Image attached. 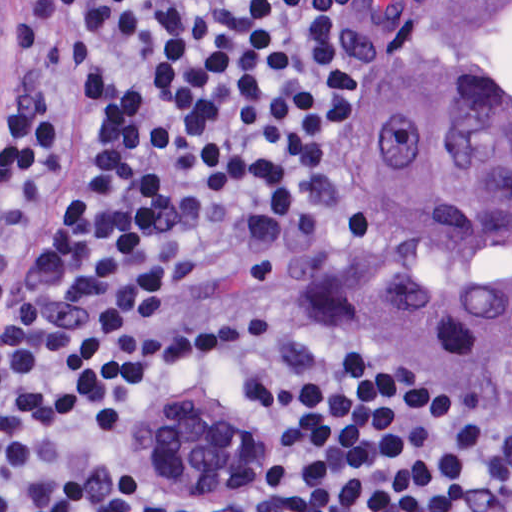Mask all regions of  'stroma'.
I'll list each match as a JSON object with an SVG mask.
<instances>
[{"label": "stroma", "instance_id": "1", "mask_svg": "<svg viewBox=\"0 0 512 512\" xmlns=\"http://www.w3.org/2000/svg\"><path fill=\"white\" fill-rule=\"evenodd\" d=\"M395 1L512 0H371V41L379 80L360 123L354 159L342 202L339 245L328 281L332 302L346 319L353 342L362 350L363 312L373 281L380 244V185L374 153L363 121L397 80L392 75L387 58L377 46V29ZM395 372L404 381L456 404L446 391Z\"/></svg>", "mask_w": 512, "mask_h": 512}]
</instances>
